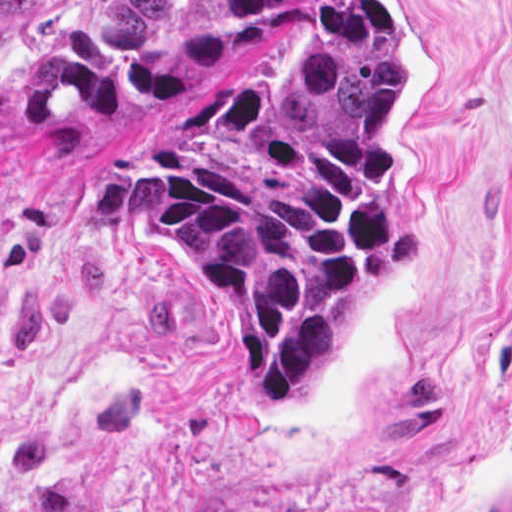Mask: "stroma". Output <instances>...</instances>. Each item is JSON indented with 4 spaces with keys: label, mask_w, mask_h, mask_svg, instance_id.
Returning a JSON list of instances; mask_svg holds the SVG:
<instances>
[{
    "label": "stroma",
    "mask_w": 512,
    "mask_h": 512,
    "mask_svg": "<svg viewBox=\"0 0 512 512\" xmlns=\"http://www.w3.org/2000/svg\"><path fill=\"white\" fill-rule=\"evenodd\" d=\"M328 1L234 71L283 78ZM377 1L403 77L396 226L421 243L366 282L287 416L255 413L213 299L129 212L208 79L7 126L96 2L42 1L0 95V512H512V0Z\"/></svg>",
    "instance_id": "obj_1"
}]
</instances>
